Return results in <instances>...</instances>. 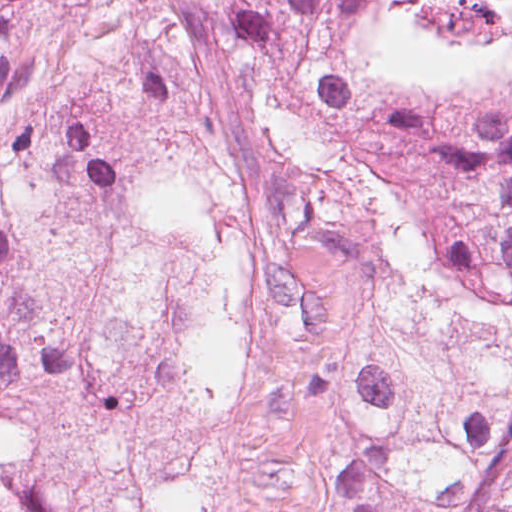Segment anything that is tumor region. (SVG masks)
Returning a JSON list of instances; mask_svg holds the SVG:
<instances>
[{"mask_svg": "<svg viewBox=\"0 0 512 512\" xmlns=\"http://www.w3.org/2000/svg\"><path fill=\"white\" fill-rule=\"evenodd\" d=\"M0 512H512V0H0Z\"/></svg>", "mask_w": 512, "mask_h": 512, "instance_id": "tumor-region-1", "label": "tumor region"}]
</instances>
